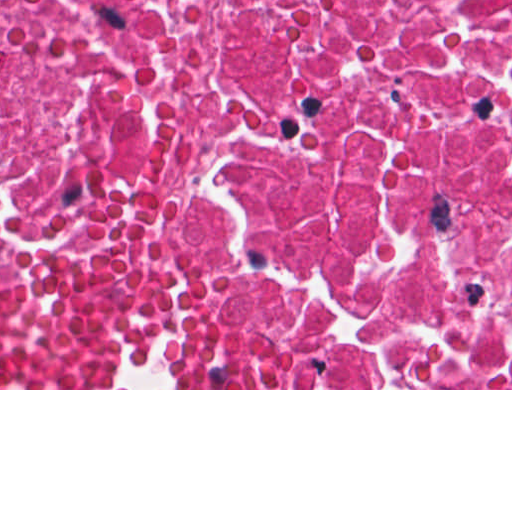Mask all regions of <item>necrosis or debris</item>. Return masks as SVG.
Masks as SVG:
<instances>
[{
	"instance_id": "necrosis-or-debris-1",
	"label": "necrosis or debris",
	"mask_w": 512,
	"mask_h": 512,
	"mask_svg": "<svg viewBox=\"0 0 512 512\" xmlns=\"http://www.w3.org/2000/svg\"><path fill=\"white\" fill-rule=\"evenodd\" d=\"M103 238L236 388H512V0H0V280Z\"/></svg>"
}]
</instances>
